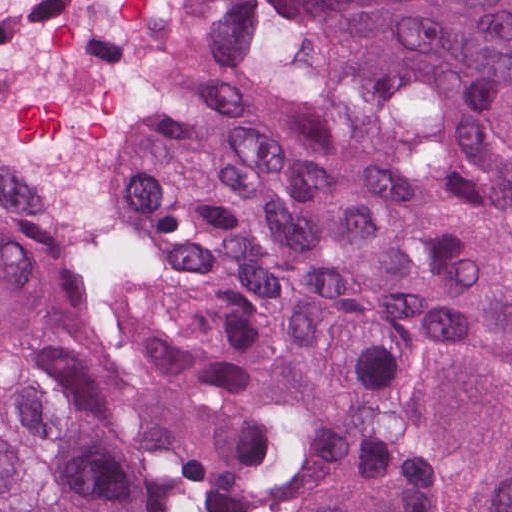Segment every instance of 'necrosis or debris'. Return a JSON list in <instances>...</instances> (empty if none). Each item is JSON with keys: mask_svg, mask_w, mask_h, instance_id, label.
Masks as SVG:
<instances>
[{"mask_svg": "<svg viewBox=\"0 0 512 512\" xmlns=\"http://www.w3.org/2000/svg\"><path fill=\"white\" fill-rule=\"evenodd\" d=\"M211 0H0V156L49 198L67 301L125 234L141 138L200 49Z\"/></svg>", "mask_w": 512, "mask_h": 512, "instance_id": "1", "label": "necrosis or debris"}]
</instances>
